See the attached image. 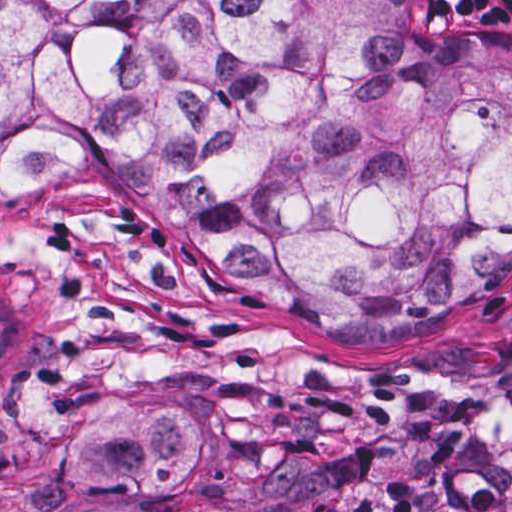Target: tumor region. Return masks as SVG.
I'll use <instances>...</instances> for the list:
<instances>
[{
  "mask_svg": "<svg viewBox=\"0 0 512 512\" xmlns=\"http://www.w3.org/2000/svg\"><path fill=\"white\" fill-rule=\"evenodd\" d=\"M97 165L329 336L433 327L512 281V44L418 0H1V187ZM42 331L1 253V368ZM210 472L205 423L116 392L49 491L166 500Z\"/></svg>",
  "mask_w": 512,
  "mask_h": 512,
  "instance_id": "tumor-region-1",
  "label": "tumor region"
}]
</instances>
